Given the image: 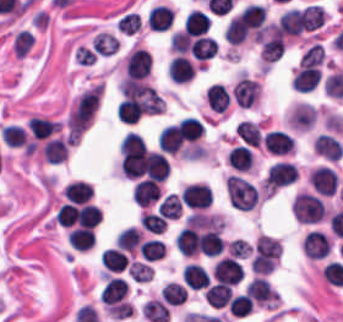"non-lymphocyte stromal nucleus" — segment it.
<instances>
[{
  "instance_id": "obj_1",
  "label": "non-lymphocyte stromal nucleus",
  "mask_w": 343,
  "mask_h": 322,
  "mask_svg": "<svg viewBox=\"0 0 343 322\" xmlns=\"http://www.w3.org/2000/svg\"><path fill=\"white\" fill-rule=\"evenodd\" d=\"M103 88L98 82L82 93L75 101L67 118V128L72 134H82L88 127L102 95Z\"/></svg>"
},
{
  "instance_id": "obj_2",
  "label": "non-lymphocyte stromal nucleus",
  "mask_w": 343,
  "mask_h": 322,
  "mask_svg": "<svg viewBox=\"0 0 343 322\" xmlns=\"http://www.w3.org/2000/svg\"><path fill=\"white\" fill-rule=\"evenodd\" d=\"M227 200L231 208L251 211L257 201L254 185L237 175H229L224 182Z\"/></svg>"
}]
</instances>
